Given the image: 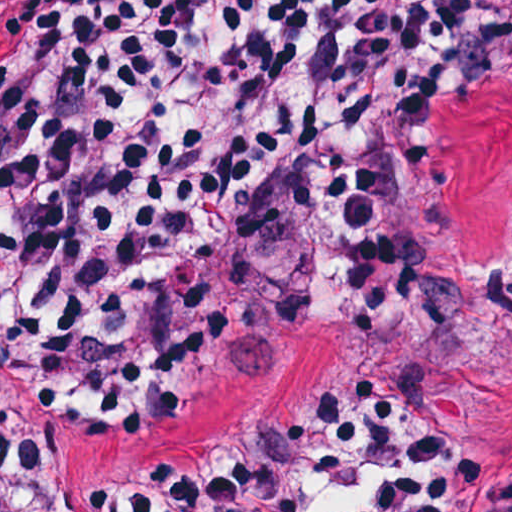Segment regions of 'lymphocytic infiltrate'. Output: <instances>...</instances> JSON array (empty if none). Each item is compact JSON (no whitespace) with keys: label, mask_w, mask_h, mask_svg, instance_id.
<instances>
[{"label":"lymphocytic infiltrate","mask_w":512,"mask_h":512,"mask_svg":"<svg viewBox=\"0 0 512 512\" xmlns=\"http://www.w3.org/2000/svg\"><path fill=\"white\" fill-rule=\"evenodd\" d=\"M512 101V0H0V511L85 409L301 322L237 463L132 512H512V453L413 393L449 122Z\"/></svg>","instance_id":"f902f5d3"}]
</instances>
